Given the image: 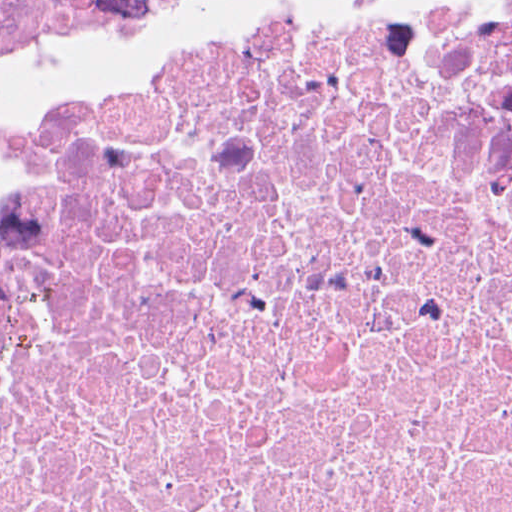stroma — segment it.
Here are the masks:
<instances>
[{
	"instance_id": "obj_1",
	"label": "stroma",
	"mask_w": 512,
	"mask_h": 512,
	"mask_svg": "<svg viewBox=\"0 0 512 512\" xmlns=\"http://www.w3.org/2000/svg\"><path fill=\"white\" fill-rule=\"evenodd\" d=\"M326 0H200L175 20L139 34L97 66L54 84L0 124V177L59 112L104 96L119 80H145L206 50L221 34L276 10Z\"/></svg>"
}]
</instances>
